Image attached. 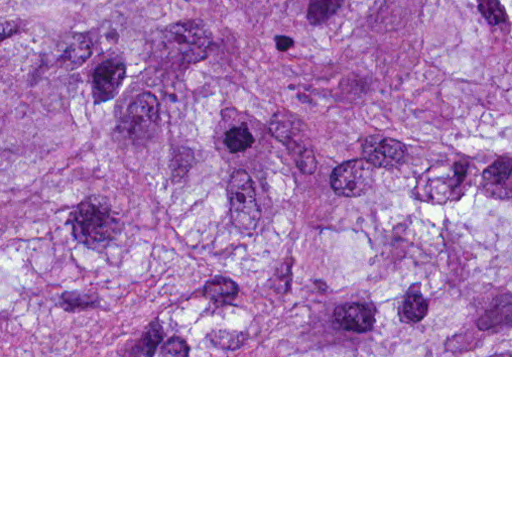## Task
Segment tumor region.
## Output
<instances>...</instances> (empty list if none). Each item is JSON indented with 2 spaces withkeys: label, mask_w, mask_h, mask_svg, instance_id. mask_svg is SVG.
Instances as JSON below:
<instances>
[{
  "label": "tumor region",
  "mask_w": 512,
  "mask_h": 512,
  "mask_svg": "<svg viewBox=\"0 0 512 512\" xmlns=\"http://www.w3.org/2000/svg\"><path fill=\"white\" fill-rule=\"evenodd\" d=\"M0 356H512V0H0Z\"/></svg>",
  "instance_id": "tumor-region-1"
}]
</instances>
